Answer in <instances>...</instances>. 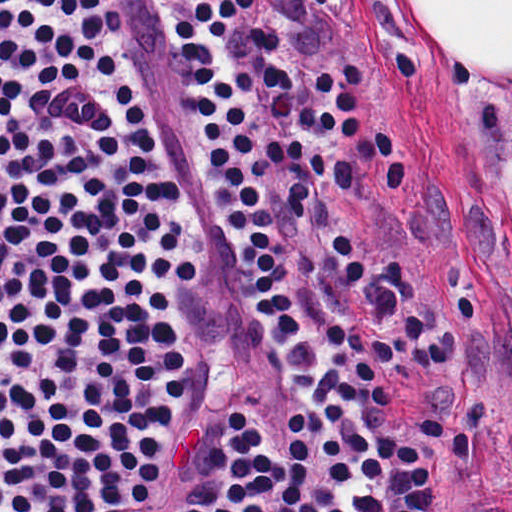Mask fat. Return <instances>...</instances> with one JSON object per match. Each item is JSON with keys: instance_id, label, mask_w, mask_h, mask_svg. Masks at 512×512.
Segmentation results:
<instances>
[{"instance_id": "obj_1", "label": "fat", "mask_w": 512, "mask_h": 512, "mask_svg": "<svg viewBox=\"0 0 512 512\" xmlns=\"http://www.w3.org/2000/svg\"><path fill=\"white\" fill-rule=\"evenodd\" d=\"M440 51L512 72V0H408ZM489 187L506 235L512 277V90L504 98L489 162Z\"/></svg>"}]
</instances>
